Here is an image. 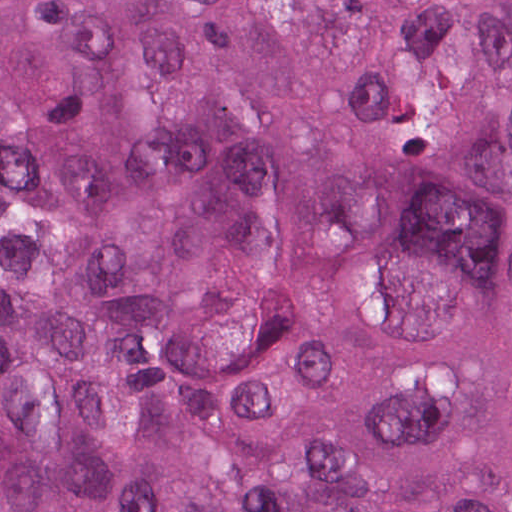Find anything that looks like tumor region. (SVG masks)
Returning <instances> with one entry per match:
<instances>
[{"mask_svg":"<svg viewBox=\"0 0 512 512\" xmlns=\"http://www.w3.org/2000/svg\"><path fill=\"white\" fill-rule=\"evenodd\" d=\"M0 512H512V0H0Z\"/></svg>","mask_w":512,"mask_h":512,"instance_id":"tumor-region-1","label":"tumor region"}]
</instances>
